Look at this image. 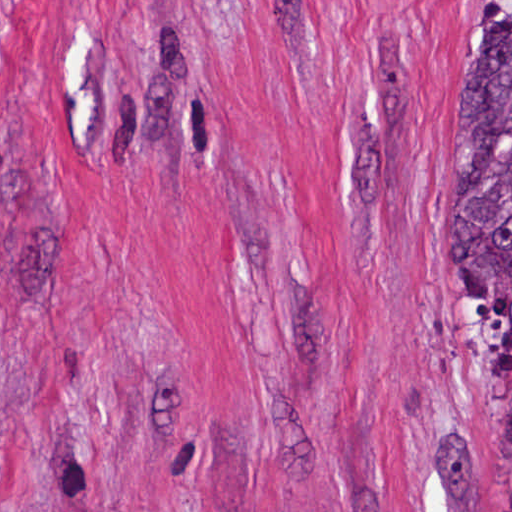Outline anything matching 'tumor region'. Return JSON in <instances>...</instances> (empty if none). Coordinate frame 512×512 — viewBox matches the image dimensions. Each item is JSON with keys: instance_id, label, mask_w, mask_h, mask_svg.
<instances>
[{"instance_id": "1", "label": "tumor region", "mask_w": 512, "mask_h": 512, "mask_svg": "<svg viewBox=\"0 0 512 512\" xmlns=\"http://www.w3.org/2000/svg\"><path fill=\"white\" fill-rule=\"evenodd\" d=\"M450 277L483 346L512 359V16L472 52L452 104ZM447 429L433 442V481L444 500L466 501L473 448ZM503 512H512V392L503 417Z\"/></svg>"}]
</instances>
